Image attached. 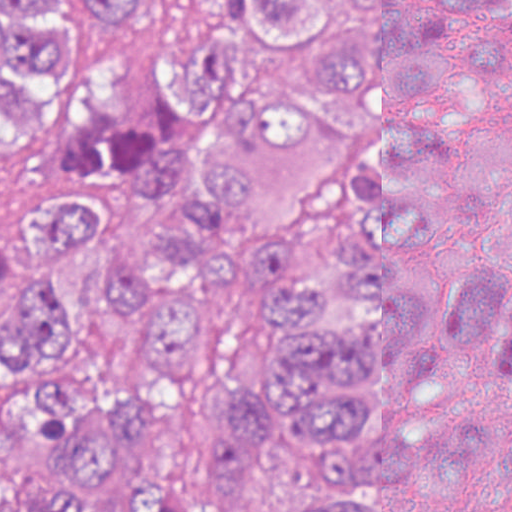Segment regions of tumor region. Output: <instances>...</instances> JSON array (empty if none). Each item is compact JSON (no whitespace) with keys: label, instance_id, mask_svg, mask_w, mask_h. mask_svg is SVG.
Wrapping results in <instances>:
<instances>
[{"label":"tumor region","instance_id":"obj_1","mask_svg":"<svg viewBox=\"0 0 512 512\" xmlns=\"http://www.w3.org/2000/svg\"><path fill=\"white\" fill-rule=\"evenodd\" d=\"M120 107L61 137L0 224V366L77 341L72 257L141 364L191 368L205 287L236 261L275 331L228 374L200 467L212 512H512V0H0V135H33L117 48ZM332 171L300 240L237 218ZM184 410L61 375L0 403V512H96L134 442ZM148 473L130 512H187Z\"/></svg>","mask_w":512,"mask_h":512}]
</instances>
